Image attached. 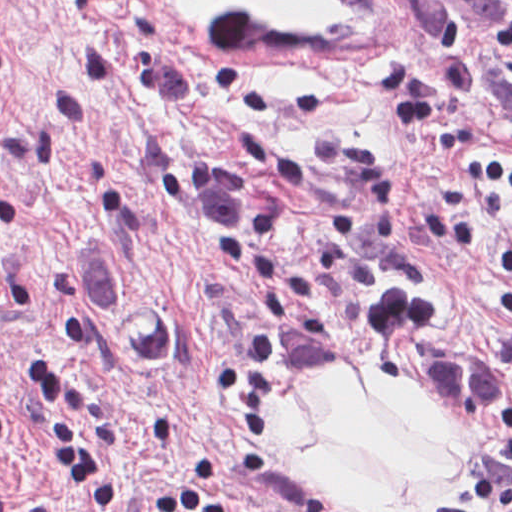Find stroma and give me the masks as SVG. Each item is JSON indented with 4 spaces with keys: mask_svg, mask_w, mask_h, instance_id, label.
<instances>
[{
    "mask_svg": "<svg viewBox=\"0 0 512 512\" xmlns=\"http://www.w3.org/2000/svg\"><path fill=\"white\" fill-rule=\"evenodd\" d=\"M226 36L182 0H0V481L13 512H357L271 447L317 373L404 379L409 349L512 350V142L441 68L415 0ZM177 328L103 355L106 308ZM28 356L62 362L122 478L56 464ZM405 380V379H404ZM460 483L417 512H482Z\"/></svg>",
    "mask_w": 512,
    "mask_h": 512,
    "instance_id": "stroma-1",
    "label": "stroma"
}]
</instances>
